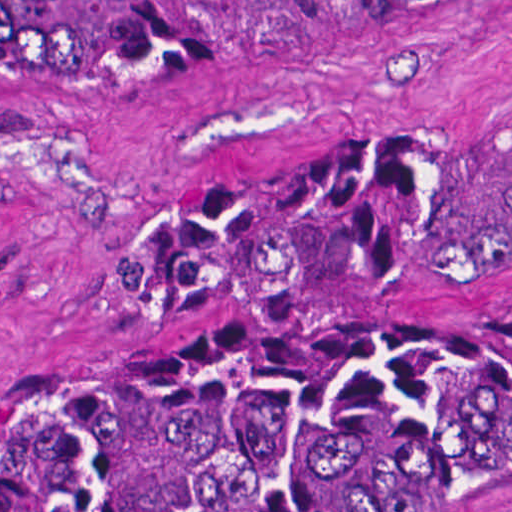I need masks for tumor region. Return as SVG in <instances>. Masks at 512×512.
<instances>
[{
    "label": "tumor region",
    "instance_id": "1",
    "mask_svg": "<svg viewBox=\"0 0 512 512\" xmlns=\"http://www.w3.org/2000/svg\"><path fill=\"white\" fill-rule=\"evenodd\" d=\"M478 0H0V76H192ZM512 280V108L302 153L126 253L139 322H272ZM512 432V323L267 324L0 413V512H368Z\"/></svg>",
    "mask_w": 512,
    "mask_h": 512
}]
</instances>
